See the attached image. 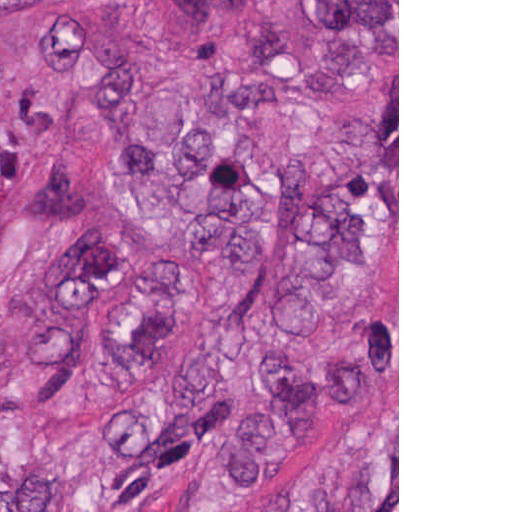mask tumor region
I'll return each instance as SVG.
<instances>
[{"label": "tumor region", "instance_id": "tumor-region-1", "mask_svg": "<svg viewBox=\"0 0 512 512\" xmlns=\"http://www.w3.org/2000/svg\"><path fill=\"white\" fill-rule=\"evenodd\" d=\"M240 0H184L205 37ZM151 0H0V43L22 66L74 80L80 154L116 157L153 223L244 309L181 363L186 279L136 252L75 159L25 194L34 231L79 238L53 264L20 335L31 392L63 389L99 348L101 308L136 294L112 343L127 389L112 420L59 432L0 414V512H147L164 484L198 478L195 512H225L285 469L397 361V319L345 337L316 328L397 283L394 149L360 121L289 112L265 74L209 71L184 91L137 62ZM288 55L383 59L397 0H280ZM371 172L375 169H380ZM20 153L0 135V216ZM142 385H147L142 387ZM251 512H397V413L288 479Z\"/></svg>", "mask_w": 512, "mask_h": 512}]
</instances>
